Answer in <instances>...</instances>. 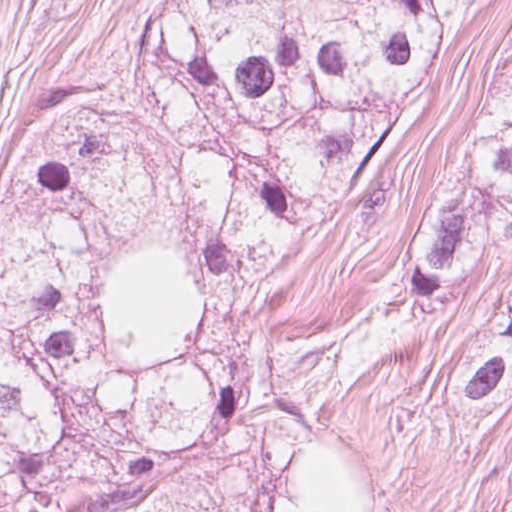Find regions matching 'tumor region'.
Here are the masks:
<instances>
[{
  "label": "tumor region",
  "mask_w": 512,
  "mask_h": 512,
  "mask_svg": "<svg viewBox=\"0 0 512 512\" xmlns=\"http://www.w3.org/2000/svg\"><path fill=\"white\" fill-rule=\"evenodd\" d=\"M488 0H158L118 78L44 121L0 225V512H390L346 418L512 249V51L402 273L305 338L263 296L410 145ZM512 400V292L458 430Z\"/></svg>",
  "instance_id": "tumor-region-1"
}]
</instances>
